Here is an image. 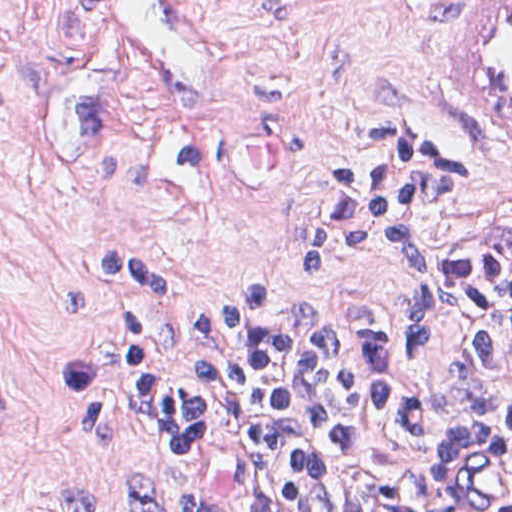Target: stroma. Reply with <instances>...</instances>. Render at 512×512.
<instances>
[{
  "instance_id": "stroma-1",
  "label": "stroma",
  "mask_w": 512,
  "mask_h": 512,
  "mask_svg": "<svg viewBox=\"0 0 512 512\" xmlns=\"http://www.w3.org/2000/svg\"><path fill=\"white\" fill-rule=\"evenodd\" d=\"M192 1L235 65L220 106L157 104L92 0H0V512H62L77 488L123 512L116 469L272 512L242 463L147 398L159 342L252 272L274 283L270 315L377 317L441 381L451 330L404 337L406 292L379 257L309 278L306 212L442 142L464 187L422 217L424 246L512 226V158L479 142L465 103L483 0Z\"/></svg>"
}]
</instances>
